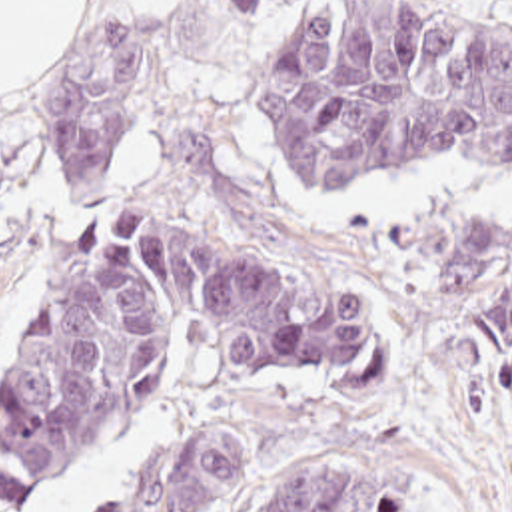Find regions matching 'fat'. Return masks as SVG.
Returning a JSON list of instances; mask_svg holds the SVG:
<instances>
[{
    "label": "fat",
    "instance_id": "53f6f03d",
    "mask_svg": "<svg viewBox=\"0 0 512 512\" xmlns=\"http://www.w3.org/2000/svg\"><path fill=\"white\" fill-rule=\"evenodd\" d=\"M177 0H127L159 11ZM91 0H0V99L27 89L73 45Z\"/></svg>",
    "mask_w": 512,
    "mask_h": 512
}]
</instances>
